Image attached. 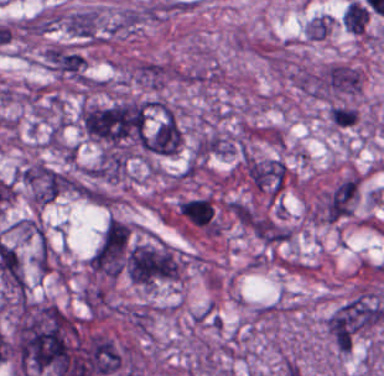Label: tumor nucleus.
Returning a JSON list of instances; mask_svg holds the SVG:
<instances>
[{
    "label": "tumor nucleus",
    "mask_w": 384,
    "mask_h": 376,
    "mask_svg": "<svg viewBox=\"0 0 384 376\" xmlns=\"http://www.w3.org/2000/svg\"><path fill=\"white\" fill-rule=\"evenodd\" d=\"M327 26L326 16H319L310 23L307 24L305 29V35L310 38L322 39Z\"/></svg>",
    "instance_id": "obj_8"
},
{
    "label": "tumor nucleus",
    "mask_w": 384,
    "mask_h": 376,
    "mask_svg": "<svg viewBox=\"0 0 384 376\" xmlns=\"http://www.w3.org/2000/svg\"><path fill=\"white\" fill-rule=\"evenodd\" d=\"M146 108L137 101L87 104L79 114L86 135L106 148L129 149L141 143Z\"/></svg>",
    "instance_id": "obj_2"
},
{
    "label": "tumor nucleus",
    "mask_w": 384,
    "mask_h": 376,
    "mask_svg": "<svg viewBox=\"0 0 384 376\" xmlns=\"http://www.w3.org/2000/svg\"><path fill=\"white\" fill-rule=\"evenodd\" d=\"M384 314L373 293L361 292L341 304L327 324L328 334L338 350H349L374 326Z\"/></svg>",
    "instance_id": "obj_3"
},
{
    "label": "tumor nucleus",
    "mask_w": 384,
    "mask_h": 376,
    "mask_svg": "<svg viewBox=\"0 0 384 376\" xmlns=\"http://www.w3.org/2000/svg\"><path fill=\"white\" fill-rule=\"evenodd\" d=\"M317 89L336 93H357L358 70L344 65H331L316 81Z\"/></svg>",
    "instance_id": "obj_6"
},
{
    "label": "tumor nucleus",
    "mask_w": 384,
    "mask_h": 376,
    "mask_svg": "<svg viewBox=\"0 0 384 376\" xmlns=\"http://www.w3.org/2000/svg\"><path fill=\"white\" fill-rule=\"evenodd\" d=\"M77 336L76 320L55 304L21 300L11 338L19 375L50 372L76 357Z\"/></svg>",
    "instance_id": "obj_1"
},
{
    "label": "tumor nucleus",
    "mask_w": 384,
    "mask_h": 376,
    "mask_svg": "<svg viewBox=\"0 0 384 376\" xmlns=\"http://www.w3.org/2000/svg\"><path fill=\"white\" fill-rule=\"evenodd\" d=\"M367 11L358 1H350L341 13V22L346 30L361 34L367 21Z\"/></svg>",
    "instance_id": "obj_7"
},
{
    "label": "tumor nucleus",
    "mask_w": 384,
    "mask_h": 376,
    "mask_svg": "<svg viewBox=\"0 0 384 376\" xmlns=\"http://www.w3.org/2000/svg\"><path fill=\"white\" fill-rule=\"evenodd\" d=\"M123 271L139 285L173 280L179 274L178 254L158 241L130 243L123 252Z\"/></svg>",
    "instance_id": "obj_4"
},
{
    "label": "tumor nucleus",
    "mask_w": 384,
    "mask_h": 376,
    "mask_svg": "<svg viewBox=\"0 0 384 376\" xmlns=\"http://www.w3.org/2000/svg\"><path fill=\"white\" fill-rule=\"evenodd\" d=\"M18 180L32 202L43 205L54 199L64 186L62 171L37 161L20 170Z\"/></svg>",
    "instance_id": "obj_5"
}]
</instances>
